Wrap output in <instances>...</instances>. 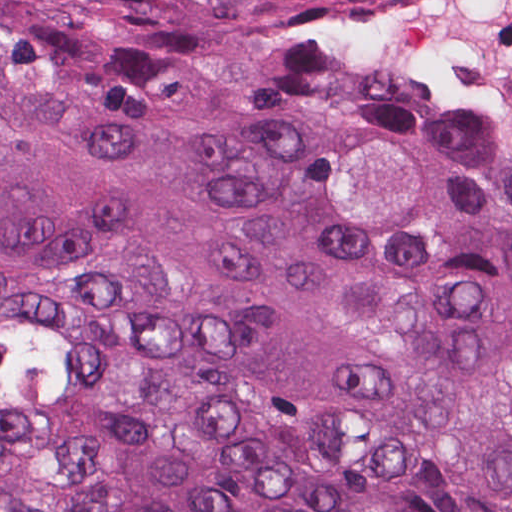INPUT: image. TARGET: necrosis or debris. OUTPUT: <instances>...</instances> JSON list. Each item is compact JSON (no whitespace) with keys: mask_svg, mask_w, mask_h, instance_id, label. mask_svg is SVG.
<instances>
[{"mask_svg":"<svg viewBox=\"0 0 512 512\" xmlns=\"http://www.w3.org/2000/svg\"><path fill=\"white\" fill-rule=\"evenodd\" d=\"M320 27L332 67L512 155V0H348Z\"/></svg>","mask_w":512,"mask_h":512,"instance_id":"necrosis-or-debris-1","label":"necrosis or debris"}]
</instances>
